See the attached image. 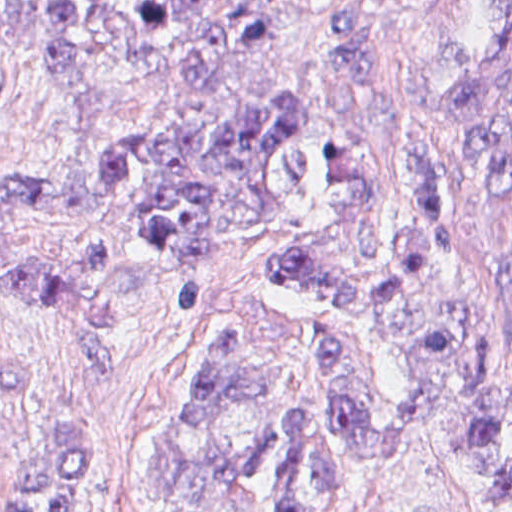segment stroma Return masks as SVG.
Returning a JSON list of instances; mask_svg holds the SVG:
<instances>
[{
    "label": "stroma",
    "instance_id": "stroma-1",
    "mask_svg": "<svg viewBox=\"0 0 512 512\" xmlns=\"http://www.w3.org/2000/svg\"><path fill=\"white\" fill-rule=\"evenodd\" d=\"M95 1L127 12L138 1H215L220 7L261 1L276 38L236 54L212 78L176 79L166 58L131 60L111 44L79 55L82 66L118 90L117 106H92L51 88L35 48L0 39V177H39L96 190L100 156L120 135L148 126L201 128L237 116L267 97L296 92L313 109L302 135L313 174L328 160L331 137L373 157L381 193V245L395 269V228L404 220V190L379 159L353 112L354 93L330 66L324 14L336 3L369 11L380 31L378 67L395 89L410 61L433 50L495 54L512 71V0H0ZM279 225L216 248L202 269V312L179 314L141 282L117 314V361L95 375L75 329L55 313L22 301L0 282V500L17 483L31 451L69 429L97 434L100 492L92 512H144L149 469L181 403L191 365L208 336L238 300L265 304L279 322L296 324L330 311L327 304L283 290L261 275L265 255L316 226L320 193L291 180L273 194ZM79 344H78V342ZM355 512H493L463 460L418 447L384 488Z\"/></svg>",
    "mask_w": 512,
    "mask_h": 512
}]
</instances>
